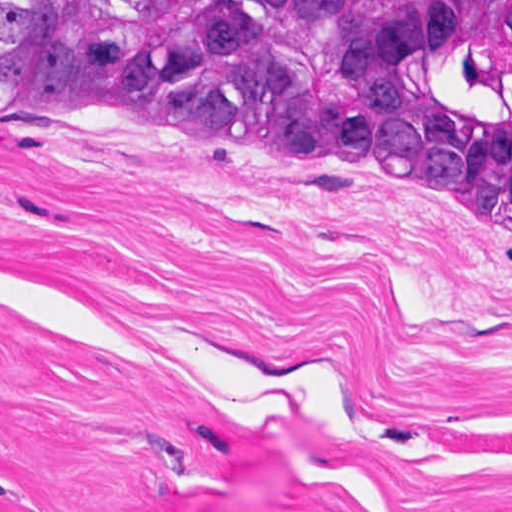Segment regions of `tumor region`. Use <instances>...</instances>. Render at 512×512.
Returning a JSON list of instances; mask_svg holds the SVG:
<instances>
[{
	"label": "tumor region",
	"instance_id": "obj_1",
	"mask_svg": "<svg viewBox=\"0 0 512 512\" xmlns=\"http://www.w3.org/2000/svg\"><path fill=\"white\" fill-rule=\"evenodd\" d=\"M0 105L193 127L382 181L512 241V0H0Z\"/></svg>",
	"mask_w": 512,
	"mask_h": 512
}]
</instances>
